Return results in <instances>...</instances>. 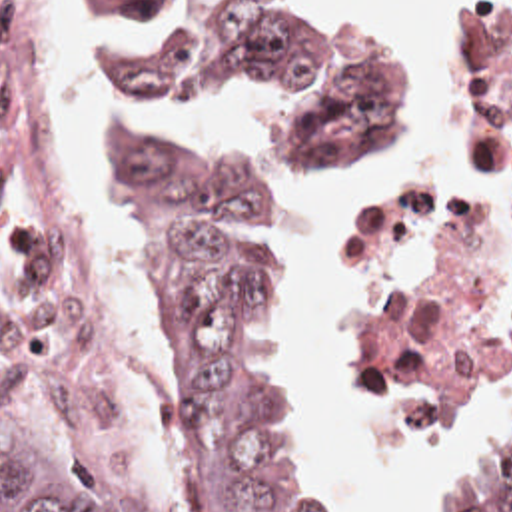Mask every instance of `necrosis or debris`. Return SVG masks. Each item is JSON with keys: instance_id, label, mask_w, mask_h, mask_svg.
<instances>
[{"instance_id": "4bbe7bcc", "label": "necrosis or debris", "mask_w": 512, "mask_h": 512, "mask_svg": "<svg viewBox=\"0 0 512 512\" xmlns=\"http://www.w3.org/2000/svg\"><path fill=\"white\" fill-rule=\"evenodd\" d=\"M367 306L431 401L491 403L512 354V0H469L437 162L373 238ZM0 320L68 443L126 461L104 280L72 202L68 0H0Z\"/></svg>"}]
</instances>
